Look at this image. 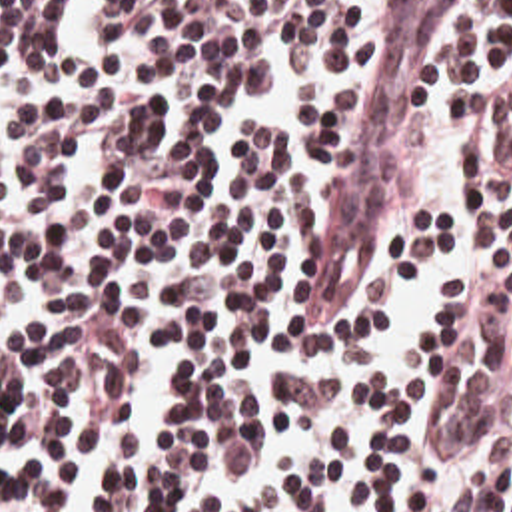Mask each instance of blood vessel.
I'll return each mask as SVG.
<instances>
[{"label":"blood vessel","mask_w":512,"mask_h":512,"mask_svg":"<svg viewBox=\"0 0 512 512\" xmlns=\"http://www.w3.org/2000/svg\"><path fill=\"white\" fill-rule=\"evenodd\" d=\"M469 0H363L345 101L317 185L293 317L379 247L429 83Z\"/></svg>","instance_id":"blood-vessel-1"}]
</instances>
